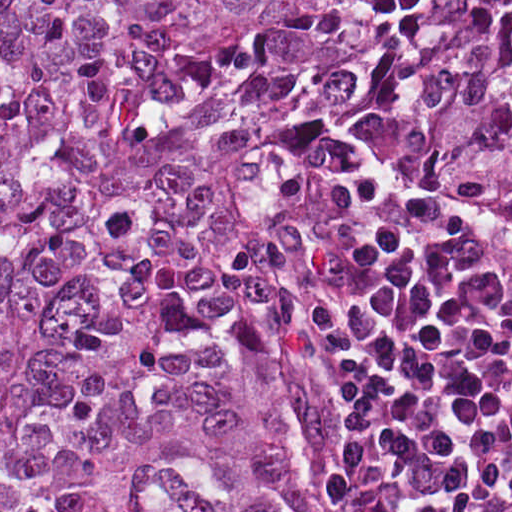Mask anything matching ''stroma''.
<instances>
[{
	"label": "stroma",
	"instance_id": "1",
	"mask_svg": "<svg viewBox=\"0 0 512 512\" xmlns=\"http://www.w3.org/2000/svg\"><path fill=\"white\" fill-rule=\"evenodd\" d=\"M353 166L370 170L442 213L479 231L494 233L512 243V217L436 181L412 176L388 157L357 149L342 154L328 169V187L315 215L312 230L283 250L276 268L274 298L281 303L302 332L312 375L324 405L340 435L341 480L334 512H354L362 483V442L330 362L307 339L300 326V277L324 237L334 184L341 172Z\"/></svg>",
	"mask_w": 512,
	"mask_h": 512
}]
</instances>
